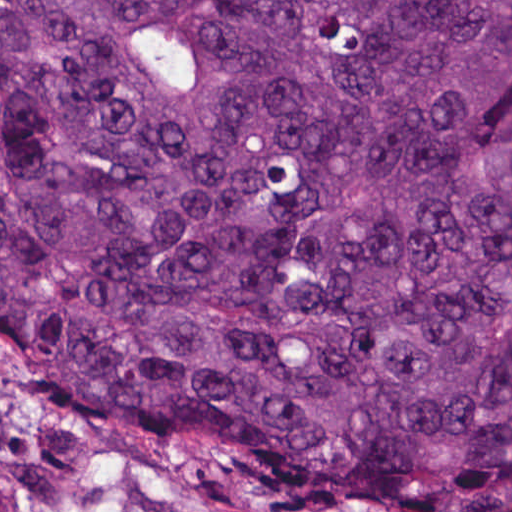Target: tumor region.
Here are the masks:
<instances>
[{
  "instance_id": "obj_1",
  "label": "tumor region",
  "mask_w": 512,
  "mask_h": 512,
  "mask_svg": "<svg viewBox=\"0 0 512 512\" xmlns=\"http://www.w3.org/2000/svg\"><path fill=\"white\" fill-rule=\"evenodd\" d=\"M0 355L334 512H512V0H0Z\"/></svg>"
}]
</instances>
